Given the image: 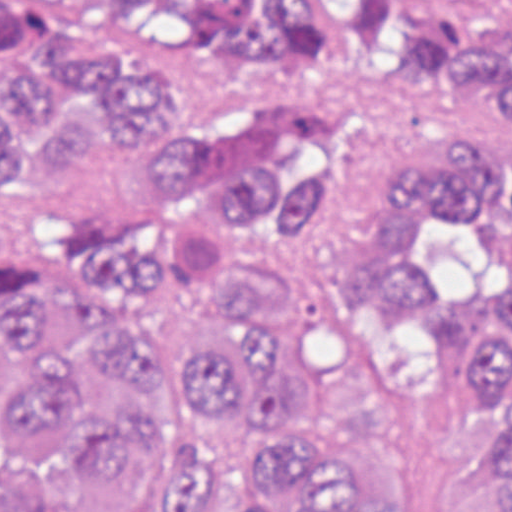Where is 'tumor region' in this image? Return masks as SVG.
I'll return each instance as SVG.
<instances>
[{
    "label": "tumor region",
    "mask_w": 512,
    "mask_h": 512,
    "mask_svg": "<svg viewBox=\"0 0 512 512\" xmlns=\"http://www.w3.org/2000/svg\"><path fill=\"white\" fill-rule=\"evenodd\" d=\"M373 53L472 127L512 143V1H0V254L39 207L77 200L121 150L143 108L199 77H314ZM488 142V141H487ZM491 147H411L390 199L379 283H417L487 405L498 466L454 512H512V156ZM142 169L195 202L223 196L281 251L269 277L218 303H190L132 223H77L45 265H0V419L38 455L82 420L77 472L110 487L157 445L185 450L167 512H194L186 464L196 437L144 412H109L73 362H45L34 336L56 315L87 358L142 385H175L223 418L244 396L286 428L314 414L337 356L338 303L303 314V341H271L251 320L256 287L303 250L347 174L342 141L287 136L245 179L218 168L202 108L147 114ZM375 482L332 443L271 438L230 512H385Z\"/></svg>",
    "instance_id": "tumor-region-1"
}]
</instances>
